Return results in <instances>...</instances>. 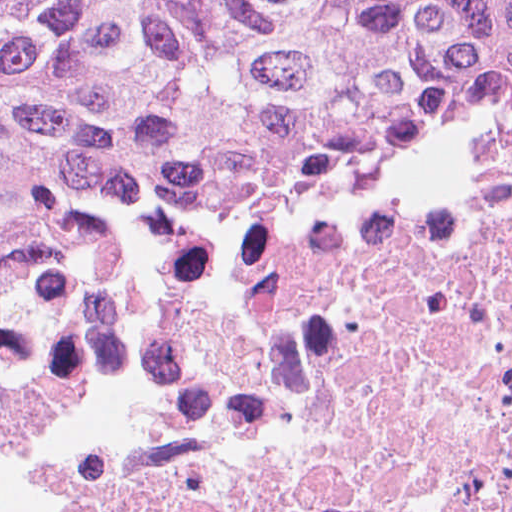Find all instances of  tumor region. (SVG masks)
<instances>
[{
    "label": "tumor region",
    "mask_w": 512,
    "mask_h": 512,
    "mask_svg": "<svg viewBox=\"0 0 512 512\" xmlns=\"http://www.w3.org/2000/svg\"><path fill=\"white\" fill-rule=\"evenodd\" d=\"M512 92V0H0V251L105 176L336 180Z\"/></svg>",
    "instance_id": "1"
}]
</instances>
